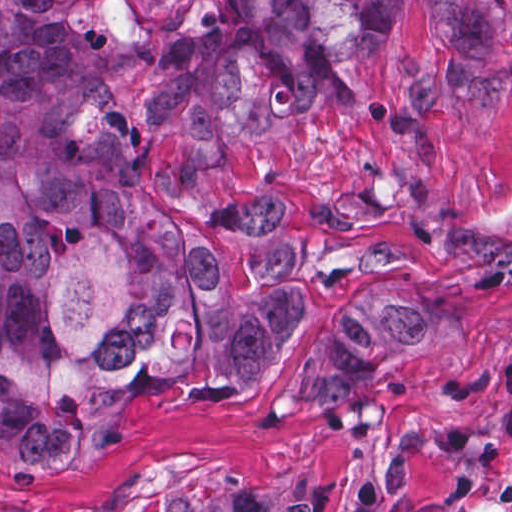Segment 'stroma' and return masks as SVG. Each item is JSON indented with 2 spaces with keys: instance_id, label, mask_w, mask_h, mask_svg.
<instances>
[{
  "instance_id": "1",
  "label": "stroma",
  "mask_w": 512,
  "mask_h": 512,
  "mask_svg": "<svg viewBox=\"0 0 512 512\" xmlns=\"http://www.w3.org/2000/svg\"><path fill=\"white\" fill-rule=\"evenodd\" d=\"M209 0H100L104 83L140 207L261 248L296 321L280 362L237 396L142 403L133 438L41 473L0 466V512H165L235 491L276 512H512V0L491 50L452 47L439 0H411L340 104L290 126L195 132L159 86ZM386 284L435 310L442 345L319 408L285 388L349 306Z\"/></svg>"
}]
</instances>
